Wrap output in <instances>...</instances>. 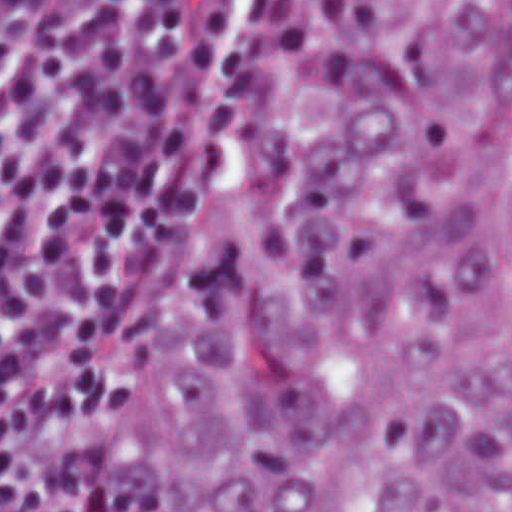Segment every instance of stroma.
Wrapping results in <instances>:
<instances>
[{
    "mask_svg": "<svg viewBox=\"0 0 512 512\" xmlns=\"http://www.w3.org/2000/svg\"><path fill=\"white\" fill-rule=\"evenodd\" d=\"M0 1H292L296 7V31L276 54L265 76L245 100L233 122L200 159L188 187L181 193L169 212L153 260V310L144 347L138 381L142 377L153 353L155 325L158 310L166 292L176 261L178 248L190 209L205 166L229 139L253 105L271 88L316 33L331 1H512V0H0ZM137 381V383H138Z\"/></svg>",
    "mask_w": 512,
    "mask_h": 512,
    "instance_id": "35a3bbf8",
    "label": "stroma"
}]
</instances>
